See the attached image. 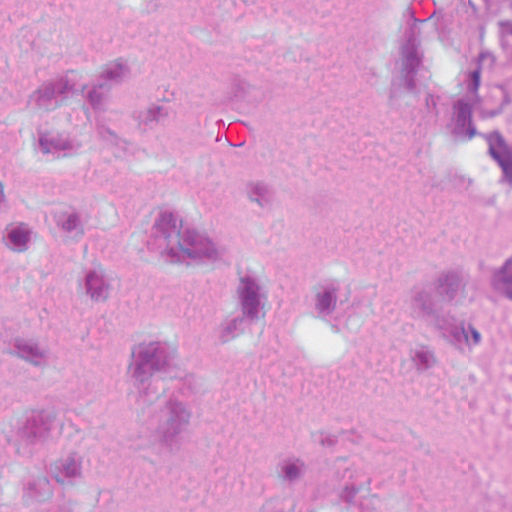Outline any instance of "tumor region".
<instances>
[{
  "label": "tumor region",
  "mask_w": 512,
  "mask_h": 512,
  "mask_svg": "<svg viewBox=\"0 0 512 512\" xmlns=\"http://www.w3.org/2000/svg\"><path fill=\"white\" fill-rule=\"evenodd\" d=\"M367 66L397 113L512 189V0H379ZM431 333L446 348L512 350V254L467 267L437 297Z\"/></svg>",
  "instance_id": "1"
}]
</instances>
